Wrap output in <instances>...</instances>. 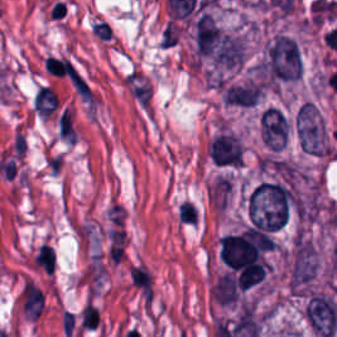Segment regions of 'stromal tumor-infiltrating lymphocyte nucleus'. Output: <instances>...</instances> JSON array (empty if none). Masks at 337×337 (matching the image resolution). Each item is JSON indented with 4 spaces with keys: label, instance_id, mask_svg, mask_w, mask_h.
I'll return each instance as SVG.
<instances>
[{
    "label": "stromal tumor-infiltrating lymphocyte nucleus",
    "instance_id": "bc302bb0",
    "mask_svg": "<svg viewBox=\"0 0 337 337\" xmlns=\"http://www.w3.org/2000/svg\"><path fill=\"white\" fill-rule=\"evenodd\" d=\"M58 99L55 93L46 85H39L33 100L35 113L40 116H48L52 113Z\"/></svg>",
    "mask_w": 337,
    "mask_h": 337
}]
</instances>
